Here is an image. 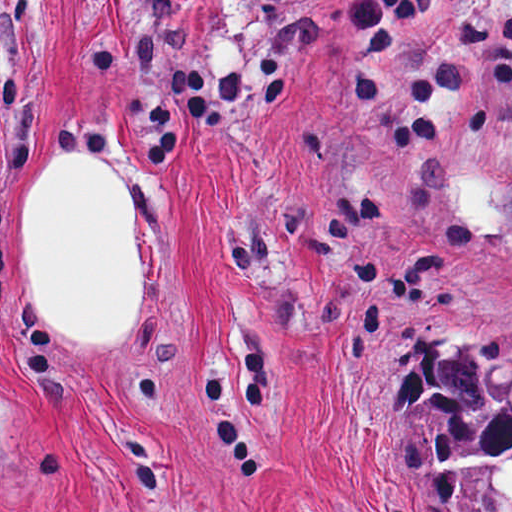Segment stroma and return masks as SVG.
I'll use <instances>...</instances> for the list:
<instances>
[{
	"instance_id": "obj_1",
	"label": "stroma",
	"mask_w": 512,
	"mask_h": 512,
	"mask_svg": "<svg viewBox=\"0 0 512 512\" xmlns=\"http://www.w3.org/2000/svg\"><path fill=\"white\" fill-rule=\"evenodd\" d=\"M341 0H0V512H436L425 335L512 341V0L368 71ZM76 146L141 218L142 322L69 344L17 248Z\"/></svg>"
}]
</instances>
